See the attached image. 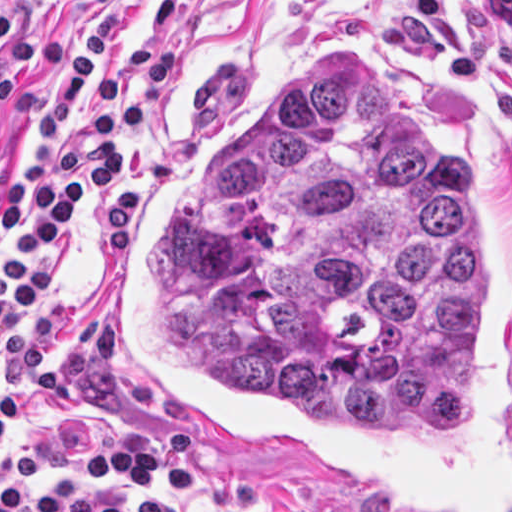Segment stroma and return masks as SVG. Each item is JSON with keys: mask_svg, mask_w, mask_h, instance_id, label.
<instances>
[{"mask_svg": "<svg viewBox=\"0 0 512 512\" xmlns=\"http://www.w3.org/2000/svg\"><path fill=\"white\" fill-rule=\"evenodd\" d=\"M98 1L0 0V11L16 10V25L2 48L17 51L28 30L38 41L36 64L9 77L14 99L0 105V263L8 252L1 191L26 163L46 57ZM115 1L110 66L119 75H132L153 44H178L182 72L163 90L153 121L127 155L122 182L76 219L57 272L30 316L1 335L3 367L20 386V407L9 439L0 445V473L31 451L83 449L128 433L172 430L130 391L106 353L109 291L148 181L191 121L294 54L308 47L359 49L424 87L449 91L512 190V140L500 117L463 98L430 57L379 46L377 36L412 0ZM197 443L198 479L177 495L156 496L183 512H366L253 454ZM31 478L38 485H94L61 470Z\"/></svg>", "mask_w": 512, "mask_h": 512, "instance_id": "1", "label": "stroma"}]
</instances>
